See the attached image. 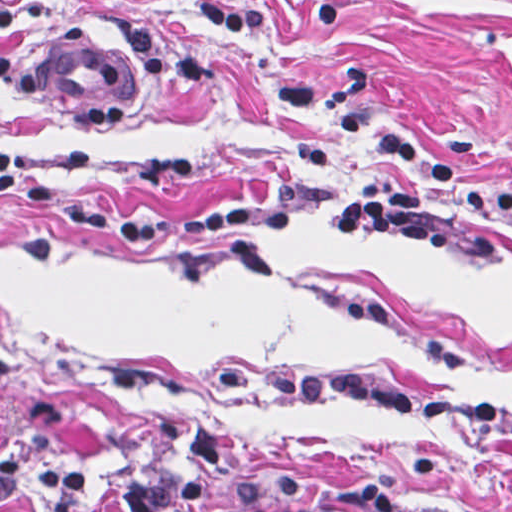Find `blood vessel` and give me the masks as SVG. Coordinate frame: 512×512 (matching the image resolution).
Here are the masks:
<instances>
[{
    "label": "blood vessel",
    "mask_w": 512,
    "mask_h": 512,
    "mask_svg": "<svg viewBox=\"0 0 512 512\" xmlns=\"http://www.w3.org/2000/svg\"><path fill=\"white\" fill-rule=\"evenodd\" d=\"M71 38L32 68L37 93L58 114L98 129L132 128L151 100V72L137 53L88 48Z\"/></svg>",
    "instance_id": "blood-vessel-1"
}]
</instances>
